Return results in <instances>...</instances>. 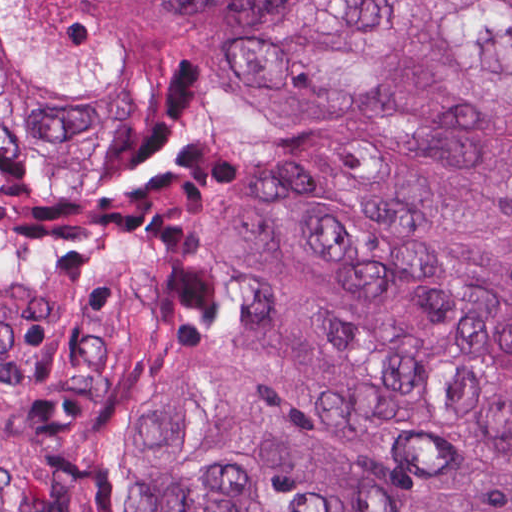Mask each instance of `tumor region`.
Segmentation results:
<instances>
[{"mask_svg":"<svg viewBox=\"0 0 512 512\" xmlns=\"http://www.w3.org/2000/svg\"><path fill=\"white\" fill-rule=\"evenodd\" d=\"M0 512H512V0H0Z\"/></svg>","mask_w":512,"mask_h":512,"instance_id":"1","label":"tumor region"}]
</instances>
